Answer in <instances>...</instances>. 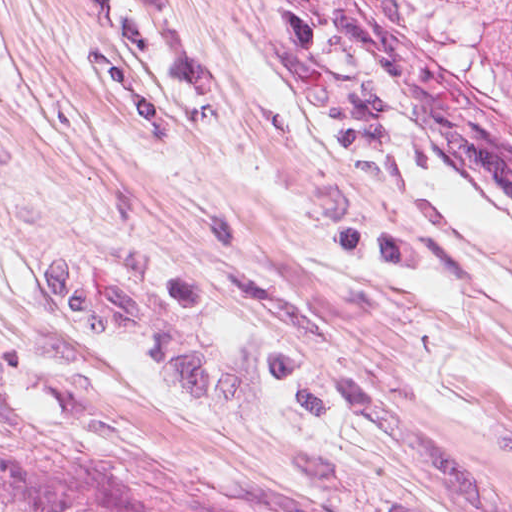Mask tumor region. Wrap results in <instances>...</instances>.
<instances>
[{
  "instance_id": "1",
  "label": "tumor region",
  "mask_w": 512,
  "mask_h": 512,
  "mask_svg": "<svg viewBox=\"0 0 512 512\" xmlns=\"http://www.w3.org/2000/svg\"><path fill=\"white\" fill-rule=\"evenodd\" d=\"M329 1L375 28L434 44L491 85L512 89V0Z\"/></svg>"
}]
</instances>
